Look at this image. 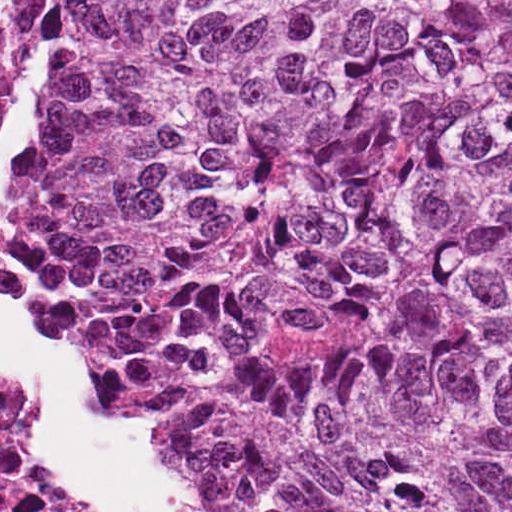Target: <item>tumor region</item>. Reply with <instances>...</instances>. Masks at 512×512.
Wrapping results in <instances>:
<instances>
[{
	"label": "tumor region",
	"mask_w": 512,
	"mask_h": 512,
	"mask_svg": "<svg viewBox=\"0 0 512 512\" xmlns=\"http://www.w3.org/2000/svg\"><path fill=\"white\" fill-rule=\"evenodd\" d=\"M20 219L197 512H512V1H6Z\"/></svg>",
	"instance_id": "e687c5a6"
}]
</instances>
